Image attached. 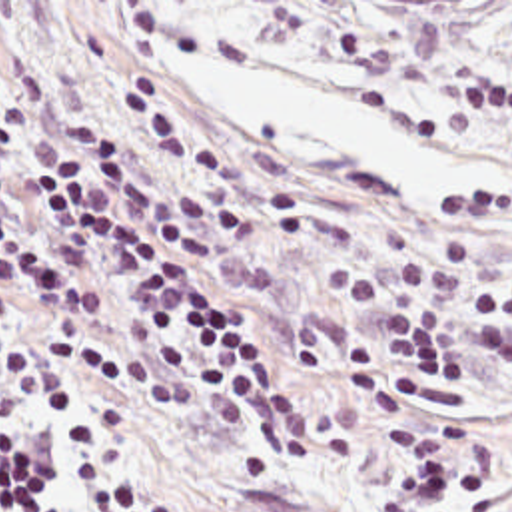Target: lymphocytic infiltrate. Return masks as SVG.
<instances>
[{
  "label": "lymphocytic infiltrate",
  "instance_id": "obj_1",
  "mask_svg": "<svg viewBox=\"0 0 512 512\" xmlns=\"http://www.w3.org/2000/svg\"><path fill=\"white\" fill-rule=\"evenodd\" d=\"M217 226L187 186L149 182L115 140L83 136L37 82L0 84V512H101L107 437L101 383L123 365L187 389L249 451L311 457L297 391L247 317L215 295ZM478 262L444 230L392 279L339 264L333 287L380 321L355 343L365 411L392 421L388 512L456 509L464 427L428 401L474 383L484 361L512 377V272L490 279L468 345L458 301L430 299ZM129 512H165L135 499Z\"/></svg>",
  "mask_w": 512,
  "mask_h": 512
}]
</instances>
